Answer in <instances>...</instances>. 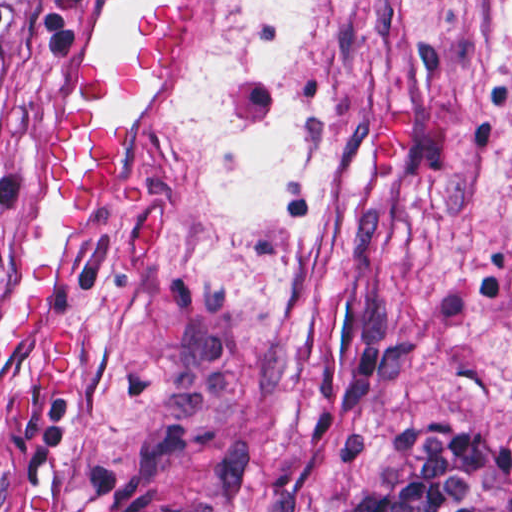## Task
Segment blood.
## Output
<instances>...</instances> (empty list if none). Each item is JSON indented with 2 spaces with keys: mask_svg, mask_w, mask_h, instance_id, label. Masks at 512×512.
Segmentation results:
<instances>
[{
  "mask_svg": "<svg viewBox=\"0 0 512 512\" xmlns=\"http://www.w3.org/2000/svg\"><path fill=\"white\" fill-rule=\"evenodd\" d=\"M196 45V20L186 11H165L138 30L115 67L103 56L81 63L71 102L56 122L41 163L50 212L57 222H74L119 183L120 143L113 129L95 125V104L145 78L166 75L187 62ZM54 263H31L27 290L0 325V362L24 348L35 351L48 400L67 391V309Z\"/></svg>",
  "mask_w": 512,
  "mask_h": 512,
  "instance_id": "1",
  "label": "blood"
}]
</instances>
